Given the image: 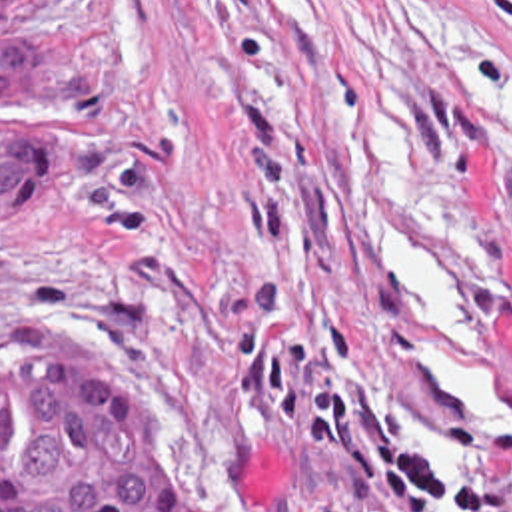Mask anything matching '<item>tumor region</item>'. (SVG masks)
Listing matches in <instances>:
<instances>
[{
    "mask_svg": "<svg viewBox=\"0 0 512 512\" xmlns=\"http://www.w3.org/2000/svg\"><path fill=\"white\" fill-rule=\"evenodd\" d=\"M54 0H0V38ZM114 94V58L80 42H0V124L84 120ZM90 178L84 130L0 126V218H54ZM0 512H202L172 474L152 392L126 362L0 382Z\"/></svg>",
    "mask_w": 512,
    "mask_h": 512,
    "instance_id": "obj_1",
    "label": "tumor region"
}]
</instances>
